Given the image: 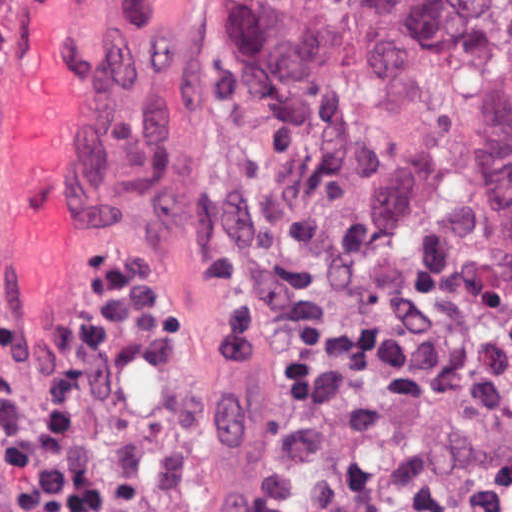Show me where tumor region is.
I'll return each instance as SVG.
<instances>
[{
  "instance_id": "tumor-region-1",
  "label": "tumor region",
  "mask_w": 512,
  "mask_h": 512,
  "mask_svg": "<svg viewBox=\"0 0 512 512\" xmlns=\"http://www.w3.org/2000/svg\"><path fill=\"white\" fill-rule=\"evenodd\" d=\"M250 267L512 313V1H221Z\"/></svg>"
}]
</instances>
